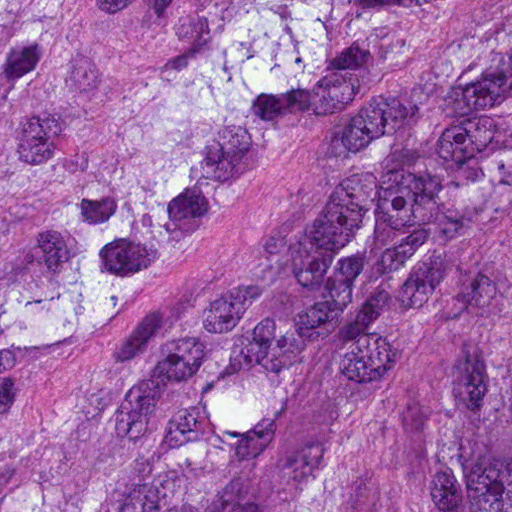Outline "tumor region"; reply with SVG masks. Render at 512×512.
<instances>
[{
	"mask_svg": "<svg viewBox=\"0 0 512 512\" xmlns=\"http://www.w3.org/2000/svg\"><path fill=\"white\" fill-rule=\"evenodd\" d=\"M98 35L0 254V512H512V0Z\"/></svg>",
	"mask_w": 512,
	"mask_h": 512,
	"instance_id": "tumor-region-1",
	"label": "tumor region"
}]
</instances>
